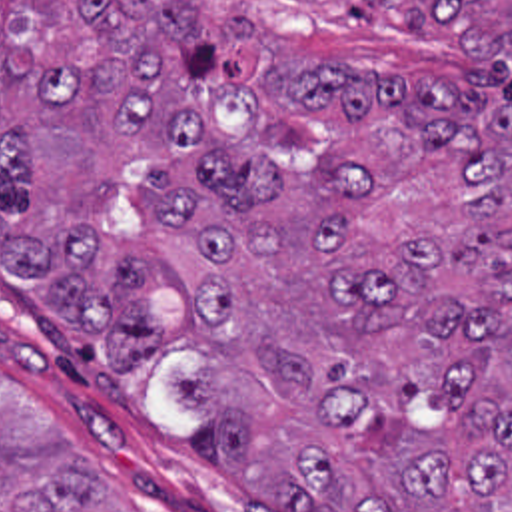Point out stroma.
<instances>
[{"mask_svg": "<svg viewBox=\"0 0 512 512\" xmlns=\"http://www.w3.org/2000/svg\"><path fill=\"white\" fill-rule=\"evenodd\" d=\"M19 11L29 0H9ZM109 339L75 327L43 285L0 261V377L41 414L129 512H284L238 486L206 412L186 407L176 375H200L176 349L127 375L107 365Z\"/></svg>", "mask_w": 512, "mask_h": 512, "instance_id": "35a3bbf8", "label": "stroma"}]
</instances>
